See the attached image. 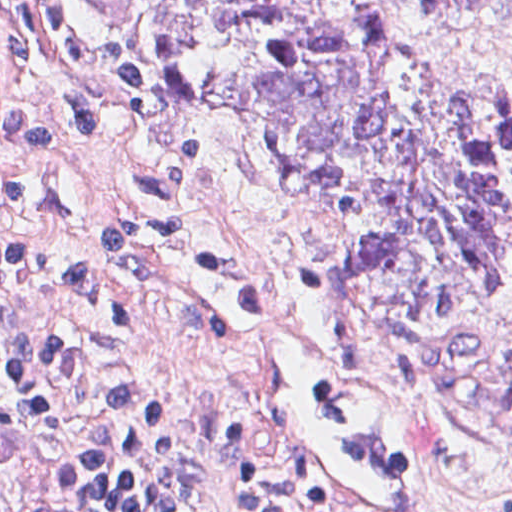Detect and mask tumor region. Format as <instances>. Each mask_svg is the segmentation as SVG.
Here are the masks:
<instances>
[{"label":"tumor region","mask_w":512,"mask_h":512,"mask_svg":"<svg viewBox=\"0 0 512 512\" xmlns=\"http://www.w3.org/2000/svg\"><path fill=\"white\" fill-rule=\"evenodd\" d=\"M391 1L512 30V0ZM145 49L203 74L259 161L334 190L360 300L412 318L512 292V91L323 0H146Z\"/></svg>","instance_id":"e687c5a6"}]
</instances>
